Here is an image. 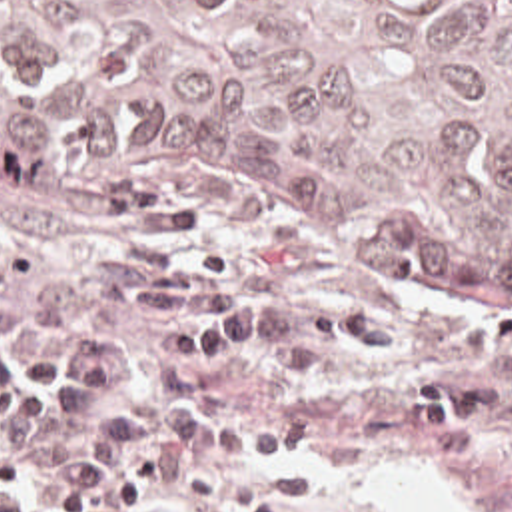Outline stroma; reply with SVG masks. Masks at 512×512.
Returning <instances> with one entry per match:
<instances>
[{
    "label": "stroma",
    "instance_id": "stroma-1",
    "mask_svg": "<svg viewBox=\"0 0 512 512\" xmlns=\"http://www.w3.org/2000/svg\"><path fill=\"white\" fill-rule=\"evenodd\" d=\"M130 245L224 261L230 287L272 309L266 343L192 393L208 421L310 427L286 455L228 461L318 469V495L290 512H378L358 487L374 465L432 475L462 512H512V309L452 305L318 241L224 215H114L0 175V331H28L46 287ZM0 491L48 512L32 485Z\"/></svg>",
    "mask_w": 512,
    "mask_h": 512
}]
</instances>
